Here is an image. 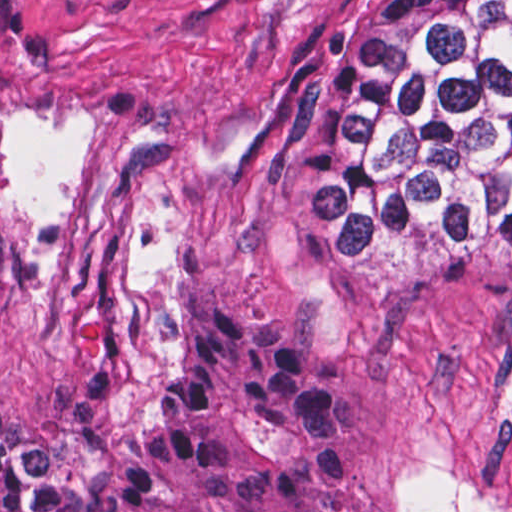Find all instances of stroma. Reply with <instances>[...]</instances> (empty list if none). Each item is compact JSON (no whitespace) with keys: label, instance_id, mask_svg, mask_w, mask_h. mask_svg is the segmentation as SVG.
Returning a JSON list of instances; mask_svg holds the SVG:
<instances>
[{"label":"stroma","instance_id":"stroma-1","mask_svg":"<svg viewBox=\"0 0 512 512\" xmlns=\"http://www.w3.org/2000/svg\"><path fill=\"white\" fill-rule=\"evenodd\" d=\"M366 0H0V416L80 430L194 295L358 383L354 512H512V228L309 250L297 156Z\"/></svg>","mask_w":512,"mask_h":512}]
</instances>
